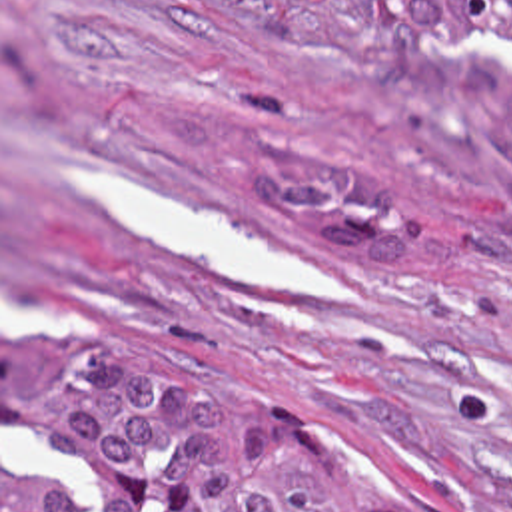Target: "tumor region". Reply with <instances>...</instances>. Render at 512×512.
Masks as SVG:
<instances>
[{
  "mask_svg": "<svg viewBox=\"0 0 512 512\" xmlns=\"http://www.w3.org/2000/svg\"><path fill=\"white\" fill-rule=\"evenodd\" d=\"M463 37L369 43L345 61L427 161L512 211V0H373ZM52 473L92 512H399L335 437L284 415L206 355L112 331L52 383ZM2 512H84L26 481L2 417Z\"/></svg>",
  "mask_w": 512,
  "mask_h": 512,
  "instance_id": "1",
  "label": "tumor region"
}]
</instances>
